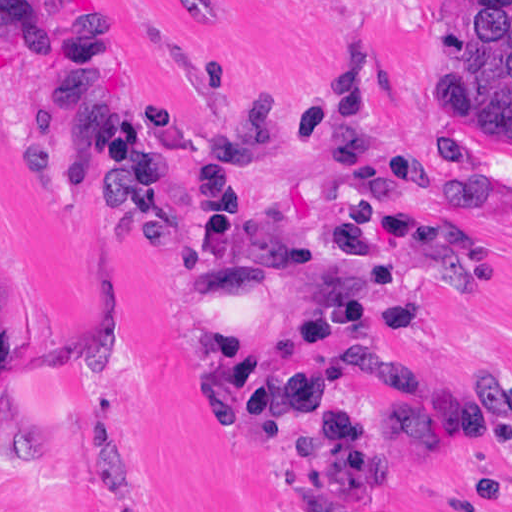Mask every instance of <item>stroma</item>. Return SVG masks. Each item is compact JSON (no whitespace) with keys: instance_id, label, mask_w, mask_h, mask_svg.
Listing matches in <instances>:
<instances>
[{"instance_id":"stroma-1","label":"stroma","mask_w":512,"mask_h":512,"mask_svg":"<svg viewBox=\"0 0 512 512\" xmlns=\"http://www.w3.org/2000/svg\"><path fill=\"white\" fill-rule=\"evenodd\" d=\"M102 25L132 105L170 100L217 124L270 103L278 151L261 196L306 198L327 158L310 119L342 70L367 84L378 152L416 159L471 235V264L436 294L430 338L297 356L363 416L396 409L403 368L471 397L512 377V132L456 101L441 45L453 0H53ZM412 155H417V158ZM191 174L170 225L146 233L97 187L55 87L6 43L0 0V512H304L277 498L264 431L228 436L222 335L279 338L289 310L258 281L216 292L188 255ZM390 512H512V462L420 441L388 458Z\"/></svg>"}]
</instances>
